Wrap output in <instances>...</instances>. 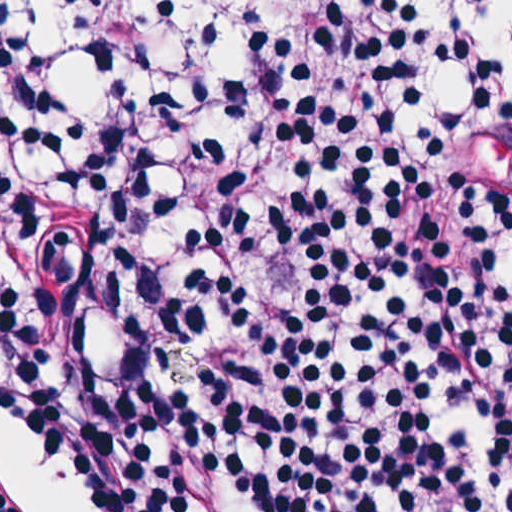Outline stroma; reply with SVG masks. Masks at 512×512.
Segmentation results:
<instances>
[{
	"instance_id": "1",
	"label": "stroma",
	"mask_w": 512,
	"mask_h": 512,
	"mask_svg": "<svg viewBox=\"0 0 512 512\" xmlns=\"http://www.w3.org/2000/svg\"><path fill=\"white\" fill-rule=\"evenodd\" d=\"M32 44L11 0H0V512L1 480L14 483L40 512H80L46 469L27 434L1 408V83L17 47Z\"/></svg>"
}]
</instances>
